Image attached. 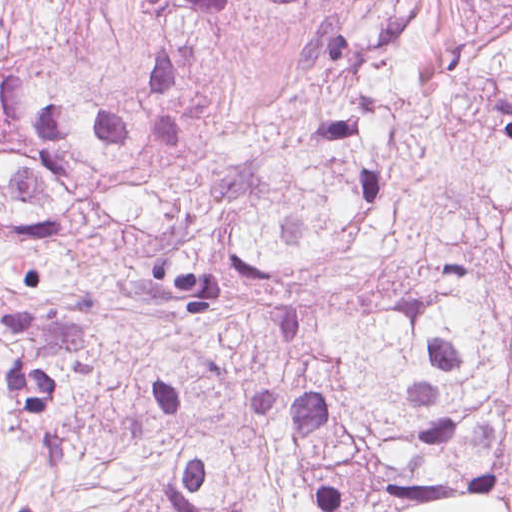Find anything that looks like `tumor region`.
I'll return each mask as SVG.
<instances>
[{
  "label": "tumor region",
  "mask_w": 512,
  "mask_h": 512,
  "mask_svg": "<svg viewBox=\"0 0 512 512\" xmlns=\"http://www.w3.org/2000/svg\"><path fill=\"white\" fill-rule=\"evenodd\" d=\"M0 0V512L512 501V0Z\"/></svg>",
  "instance_id": "e687c5a6"
}]
</instances>
